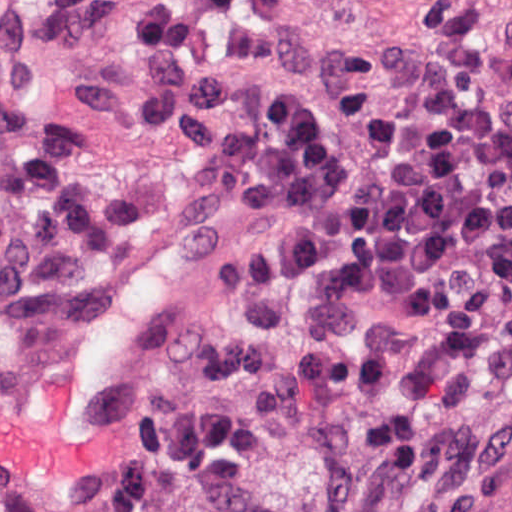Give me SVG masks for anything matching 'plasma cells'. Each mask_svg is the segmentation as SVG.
<instances>
[{
    "instance_id": "obj_1",
    "label": "plasma cells",
    "mask_w": 512,
    "mask_h": 512,
    "mask_svg": "<svg viewBox=\"0 0 512 512\" xmlns=\"http://www.w3.org/2000/svg\"><path fill=\"white\" fill-rule=\"evenodd\" d=\"M40 39L34 19L0 24V308L15 327L44 321L148 210L84 165V124L40 91ZM137 51L151 140L200 165L225 211L303 229L224 274L240 314L213 336L197 394L152 417L86 512H152L165 484L186 512H279L265 463L290 431L304 442L313 512H356L373 468L395 483L464 484L488 448L487 412L434 349L329 339L300 324L299 306L324 290L382 294L512 382V117L417 111L343 87L328 107L286 89L253 121L234 83L180 57L162 6H146Z\"/></svg>"
}]
</instances>
